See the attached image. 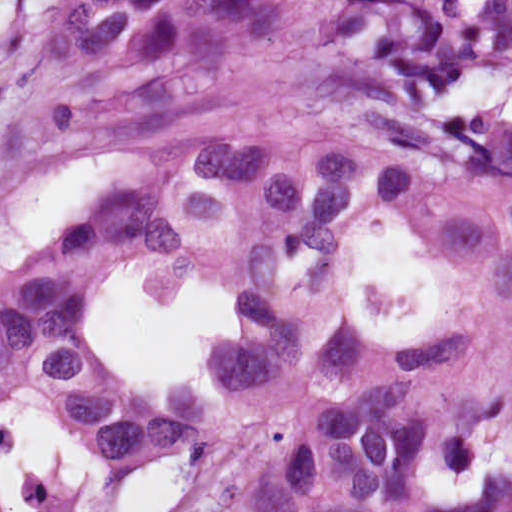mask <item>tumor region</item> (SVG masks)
Here are the masks:
<instances>
[{
	"instance_id": "e687c5a6",
	"label": "tumor region",
	"mask_w": 512,
	"mask_h": 512,
	"mask_svg": "<svg viewBox=\"0 0 512 512\" xmlns=\"http://www.w3.org/2000/svg\"><path fill=\"white\" fill-rule=\"evenodd\" d=\"M511 62L512 0H59L0 80V174L117 163L0 276V405L33 404L122 483L214 445L255 387L302 379L231 512L440 509L426 474L512 440V357L447 363L512 321V128L469 86ZM376 222L441 277L400 343L348 309ZM136 261L227 285L221 389L158 396L91 337Z\"/></svg>"
}]
</instances>
